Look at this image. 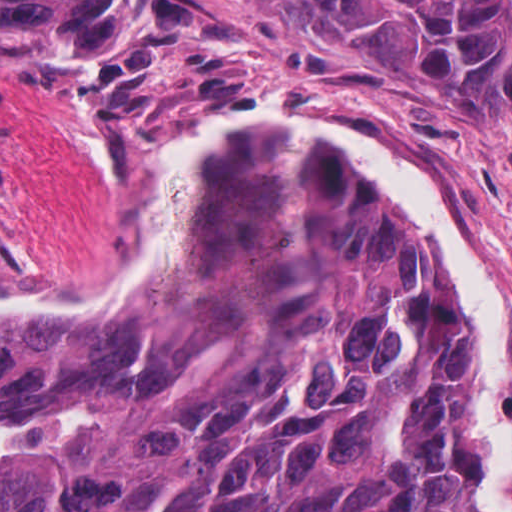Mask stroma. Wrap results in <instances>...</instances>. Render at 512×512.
<instances>
[{
	"mask_svg": "<svg viewBox=\"0 0 512 512\" xmlns=\"http://www.w3.org/2000/svg\"><path fill=\"white\" fill-rule=\"evenodd\" d=\"M142 1L153 50L0 57V239L16 255L0 286L47 298L103 286L184 143L228 110L282 105L385 136L445 185L486 251L512 353V106L480 123L433 117L384 44L285 0Z\"/></svg>",
	"mask_w": 512,
	"mask_h": 512,
	"instance_id": "1",
	"label": "stroma"
}]
</instances>
